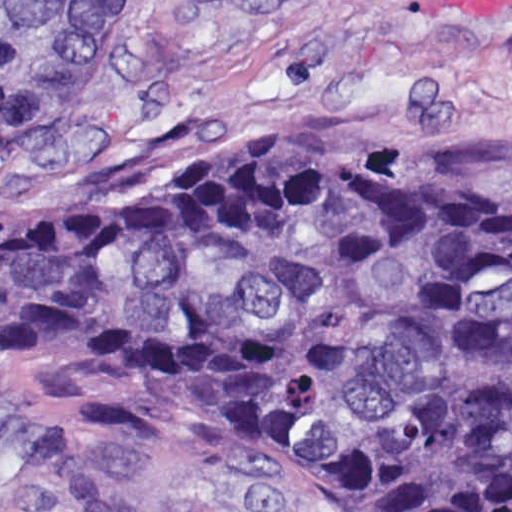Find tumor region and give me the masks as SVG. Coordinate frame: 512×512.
Returning <instances> with one entry per match:
<instances>
[{"mask_svg": "<svg viewBox=\"0 0 512 512\" xmlns=\"http://www.w3.org/2000/svg\"><path fill=\"white\" fill-rule=\"evenodd\" d=\"M135 0H0V161L86 100ZM271 132L0 216V449L34 358L252 428L412 512H512V166Z\"/></svg>", "mask_w": 512, "mask_h": 512, "instance_id": "tumor-region-1", "label": "tumor region"}]
</instances>
